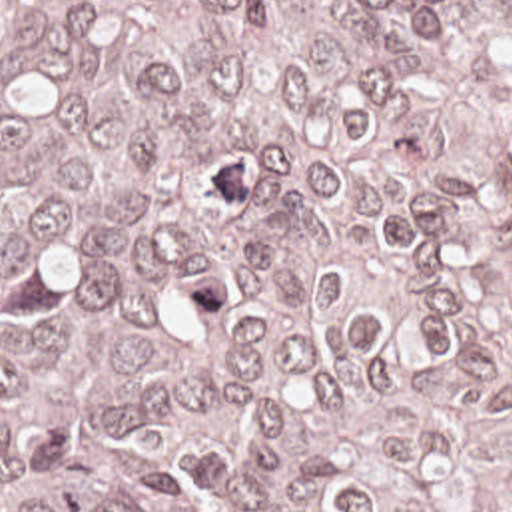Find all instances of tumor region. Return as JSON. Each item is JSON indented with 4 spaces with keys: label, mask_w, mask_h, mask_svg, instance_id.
<instances>
[{
    "label": "tumor region",
    "mask_w": 512,
    "mask_h": 512,
    "mask_svg": "<svg viewBox=\"0 0 512 512\" xmlns=\"http://www.w3.org/2000/svg\"><path fill=\"white\" fill-rule=\"evenodd\" d=\"M0 512H512V0H0Z\"/></svg>",
    "instance_id": "1"
}]
</instances>
